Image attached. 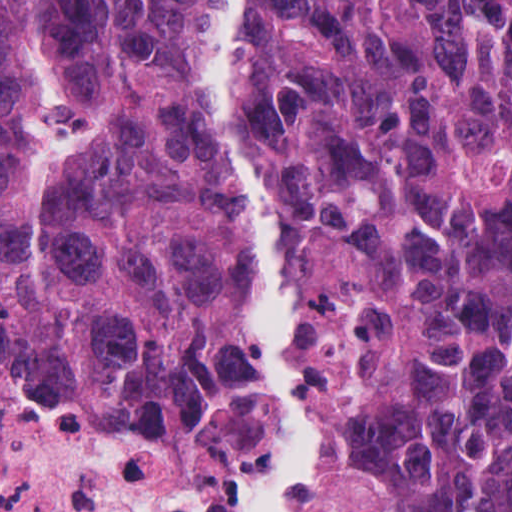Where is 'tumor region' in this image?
Segmentation results:
<instances>
[{
    "mask_svg": "<svg viewBox=\"0 0 512 512\" xmlns=\"http://www.w3.org/2000/svg\"><path fill=\"white\" fill-rule=\"evenodd\" d=\"M231 153L282 230L314 512H512V0H242ZM266 244L202 0H0V374L257 512Z\"/></svg>",
    "mask_w": 512,
    "mask_h": 512,
    "instance_id": "obj_1",
    "label": "tumor region"
}]
</instances>
